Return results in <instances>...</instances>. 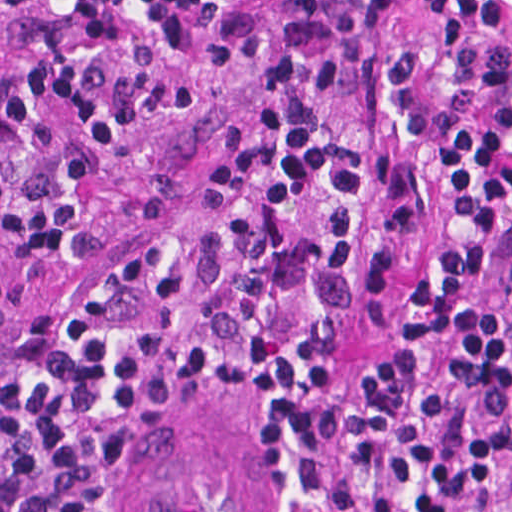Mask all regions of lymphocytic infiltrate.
I'll use <instances>...</instances> for the list:
<instances>
[{"mask_svg": "<svg viewBox=\"0 0 512 512\" xmlns=\"http://www.w3.org/2000/svg\"><path fill=\"white\" fill-rule=\"evenodd\" d=\"M416 2V40L374 65L388 148L361 157L375 220L413 245L396 349H332L392 258L318 105L389 0H235L206 43L256 59L261 96L204 182L14 339L0 512H116L140 427L244 384L263 397L252 512H512L509 320L470 298L480 267H512V0Z\"/></svg>", "mask_w": 512, "mask_h": 512, "instance_id": "lymphocytic-infiltrate-1", "label": "lymphocytic infiltrate"}]
</instances>
